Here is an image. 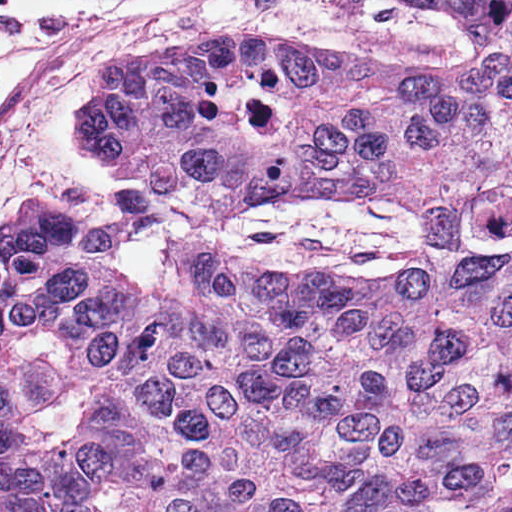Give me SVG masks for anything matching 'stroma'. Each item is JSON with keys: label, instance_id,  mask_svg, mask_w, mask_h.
<instances>
[{"label": "stroma", "instance_id": "stroma-1", "mask_svg": "<svg viewBox=\"0 0 512 512\" xmlns=\"http://www.w3.org/2000/svg\"><path fill=\"white\" fill-rule=\"evenodd\" d=\"M164 37L322 44L378 68L450 64L461 45L457 25L409 0H182L106 22L41 64L0 122V229L46 198L84 214L142 281H166L170 242L326 285L411 257L418 218L401 206L302 184L274 207L212 215L103 160L75 112L112 59Z\"/></svg>", "mask_w": 512, "mask_h": 512}]
</instances>
